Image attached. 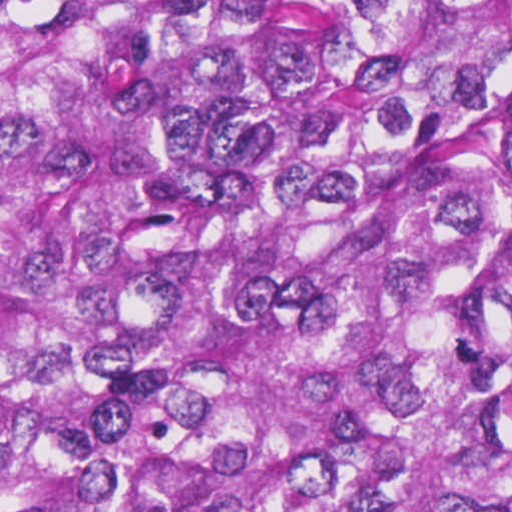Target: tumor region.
I'll list each match as a JSON object with an SVG mask.
<instances>
[{"label": "tumor region", "mask_w": 512, "mask_h": 512, "mask_svg": "<svg viewBox=\"0 0 512 512\" xmlns=\"http://www.w3.org/2000/svg\"><path fill=\"white\" fill-rule=\"evenodd\" d=\"M0 512H512V0H0Z\"/></svg>", "instance_id": "obj_1"}]
</instances>
